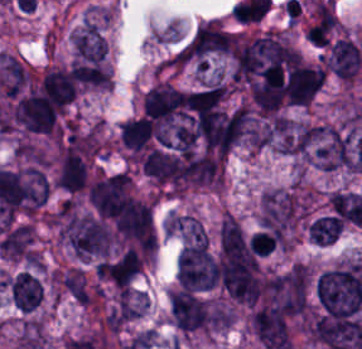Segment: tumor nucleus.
<instances>
[{"label":"tumor nucleus","instance_id":"obj_5","mask_svg":"<svg viewBox=\"0 0 362 349\" xmlns=\"http://www.w3.org/2000/svg\"><path fill=\"white\" fill-rule=\"evenodd\" d=\"M166 234L181 242L208 243V231L200 219L186 213H171L162 224Z\"/></svg>","mask_w":362,"mask_h":349},{"label":"tumor nucleus","instance_id":"obj_9","mask_svg":"<svg viewBox=\"0 0 362 349\" xmlns=\"http://www.w3.org/2000/svg\"><path fill=\"white\" fill-rule=\"evenodd\" d=\"M343 221L331 214L316 217L308 228L311 242L330 244L339 234Z\"/></svg>","mask_w":362,"mask_h":349},{"label":"tumor nucleus","instance_id":"obj_6","mask_svg":"<svg viewBox=\"0 0 362 349\" xmlns=\"http://www.w3.org/2000/svg\"><path fill=\"white\" fill-rule=\"evenodd\" d=\"M12 303L20 310L30 312L40 302L42 286L30 271H21L10 278Z\"/></svg>","mask_w":362,"mask_h":349},{"label":"tumor nucleus","instance_id":"obj_4","mask_svg":"<svg viewBox=\"0 0 362 349\" xmlns=\"http://www.w3.org/2000/svg\"><path fill=\"white\" fill-rule=\"evenodd\" d=\"M141 268V256L134 248H125L100 261L95 267L99 277L124 288Z\"/></svg>","mask_w":362,"mask_h":349},{"label":"tumor nucleus","instance_id":"obj_1","mask_svg":"<svg viewBox=\"0 0 362 349\" xmlns=\"http://www.w3.org/2000/svg\"><path fill=\"white\" fill-rule=\"evenodd\" d=\"M59 239L75 258L89 261L107 256L112 233L99 217L74 213L65 218Z\"/></svg>","mask_w":362,"mask_h":349},{"label":"tumor nucleus","instance_id":"obj_8","mask_svg":"<svg viewBox=\"0 0 362 349\" xmlns=\"http://www.w3.org/2000/svg\"><path fill=\"white\" fill-rule=\"evenodd\" d=\"M58 282L79 304H90L93 288L83 269L77 266L63 269L59 274Z\"/></svg>","mask_w":362,"mask_h":349},{"label":"tumor nucleus","instance_id":"obj_2","mask_svg":"<svg viewBox=\"0 0 362 349\" xmlns=\"http://www.w3.org/2000/svg\"><path fill=\"white\" fill-rule=\"evenodd\" d=\"M176 277L184 289L208 290L219 281L218 264L207 246L195 238L182 247Z\"/></svg>","mask_w":362,"mask_h":349},{"label":"tumor nucleus","instance_id":"obj_3","mask_svg":"<svg viewBox=\"0 0 362 349\" xmlns=\"http://www.w3.org/2000/svg\"><path fill=\"white\" fill-rule=\"evenodd\" d=\"M362 64V49L349 37L341 36L328 48L325 65L347 81H352Z\"/></svg>","mask_w":362,"mask_h":349},{"label":"tumor nucleus","instance_id":"obj_7","mask_svg":"<svg viewBox=\"0 0 362 349\" xmlns=\"http://www.w3.org/2000/svg\"><path fill=\"white\" fill-rule=\"evenodd\" d=\"M70 38L80 58L100 60L103 56L105 41L94 23L87 20L73 31Z\"/></svg>","mask_w":362,"mask_h":349}]
</instances>
